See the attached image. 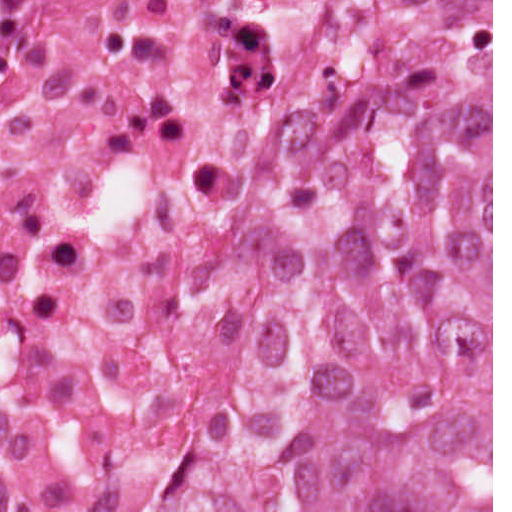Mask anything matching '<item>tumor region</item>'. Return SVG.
<instances>
[{
  "instance_id": "tumor-region-1",
  "label": "tumor region",
  "mask_w": 512,
  "mask_h": 512,
  "mask_svg": "<svg viewBox=\"0 0 512 512\" xmlns=\"http://www.w3.org/2000/svg\"><path fill=\"white\" fill-rule=\"evenodd\" d=\"M170 512H491V1H367L298 129L282 298Z\"/></svg>"
}]
</instances>
